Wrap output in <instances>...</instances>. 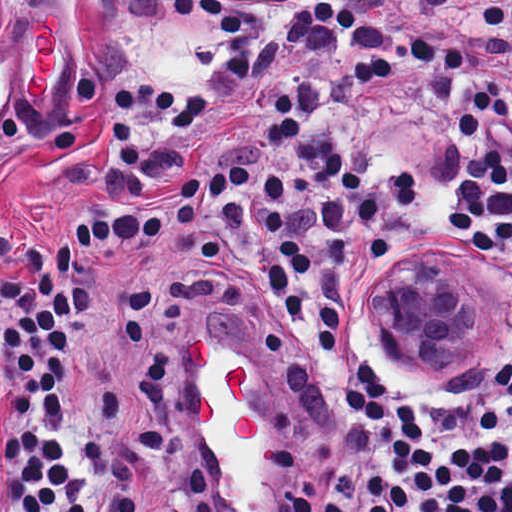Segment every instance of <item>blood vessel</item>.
<instances>
[{"label":"blood vessel","mask_w":512,"mask_h":512,"mask_svg":"<svg viewBox=\"0 0 512 512\" xmlns=\"http://www.w3.org/2000/svg\"><path fill=\"white\" fill-rule=\"evenodd\" d=\"M63 19L52 9L37 13L29 30L23 56V93L33 101L47 95L57 80L62 62ZM18 71L0 65V101Z\"/></svg>","instance_id":"8fb6f2fc"}]
</instances>
